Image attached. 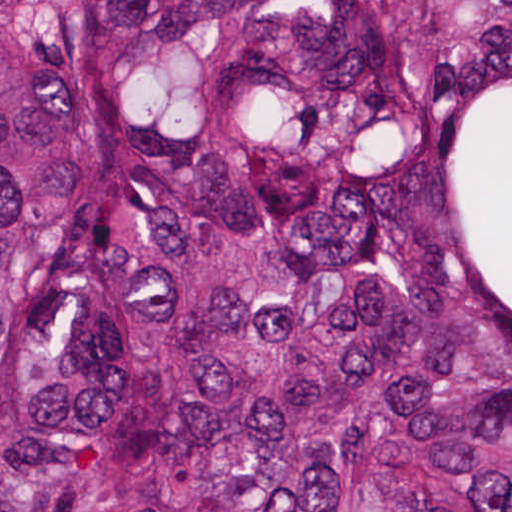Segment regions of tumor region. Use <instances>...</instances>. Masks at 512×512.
Wrapping results in <instances>:
<instances>
[{
	"label": "tumor region",
	"instance_id": "1",
	"mask_svg": "<svg viewBox=\"0 0 512 512\" xmlns=\"http://www.w3.org/2000/svg\"><path fill=\"white\" fill-rule=\"evenodd\" d=\"M0 512H512V0H0Z\"/></svg>",
	"mask_w": 512,
	"mask_h": 512
}]
</instances>
